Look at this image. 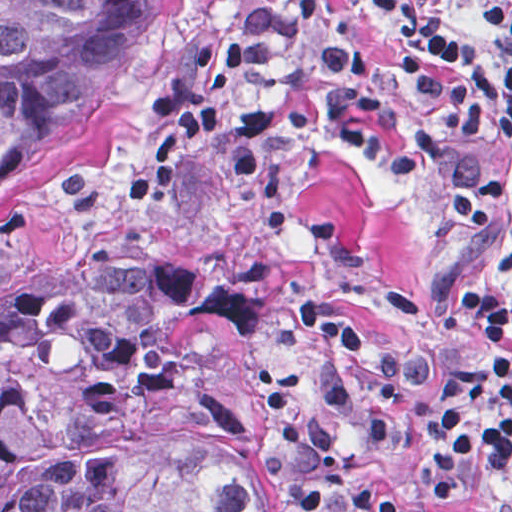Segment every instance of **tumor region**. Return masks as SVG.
I'll return each instance as SVG.
<instances>
[{"instance_id": "e687c5a6", "label": "tumor region", "mask_w": 512, "mask_h": 512, "mask_svg": "<svg viewBox=\"0 0 512 512\" xmlns=\"http://www.w3.org/2000/svg\"><path fill=\"white\" fill-rule=\"evenodd\" d=\"M154 0H0V211L63 190L102 145ZM268 313L168 250L0 279V512H260L238 398L196 316Z\"/></svg>"}]
</instances>
